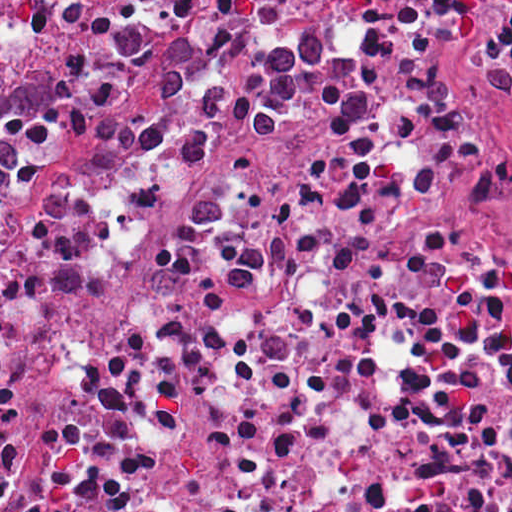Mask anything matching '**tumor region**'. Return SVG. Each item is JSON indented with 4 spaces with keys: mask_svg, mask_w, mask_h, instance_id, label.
<instances>
[{
    "mask_svg": "<svg viewBox=\"0 0 512 512\" xmlns=\"http://www.w3.org/2000/svg\"><path fill=\"white\" fill-rule=\"evenodd\" d=\"M56 103V81H0V184L13 168L12 151L1 131L10 115L44 112Z\"/></svg>",
    "mask_w": 512,
    "mask_h": 512,
    "instance_id": "tumor-region-1",
    "label": "tumor region"
}]
</instances>
